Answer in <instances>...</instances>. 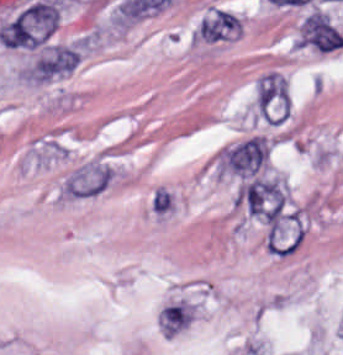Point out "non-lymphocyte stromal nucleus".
<instances>
[{
	"mask_svg": "<svg viewBox=\"0 0 343 355\" xmlns=\"http://www.w3.org/2000/svg\"><path fill=\"white\" fill-rule=\"evenodd\" d=\"M243 207L261 221L277 226L284 219L285 196L274 180L251 176L240 191Z\"/></svg>",
	"mask_w": 343,
	"mask_h": 355,
	"instance_id": "dd21d789",
	"label": "non-lymphocyte stromal nucleus"
},
{
	"mask_svg": "<svg viewBox=\"0 0 343 355\" xmlns=\"http://www.w3.org/2000/svg\"><path fill=\"white\" fill-rule=\"evenodd\" d=\"M114 173L109 163L87 160L73 168L60 182L59 193L63 196H95L106 187Z\"/></svg>",
	"mask_w": 343,
	"mask_h": 355,
	"instance_id": "a72fc3eb",
	"label": "non-lymphocyte stromal nucleus"
},
{
	"mask_svg": "<svg viewBox=\"0 0 343 355\" xmlns=\"http://www.w3.org/2000/svg\"><path fill=\"white\" fill-rule=\"evenodd\" d=\"M300 45L328 51L343 45V37L326 14L314 11L303 22Z\"/></svg>",
	"mask_w": 343,
	"mask_h": 355,
	"instance_id": "3746e769",
	"label": "non-lymphocyte stromal nucleus"
},
{
	"mask_svg": "<svg viewBox=\"0 0 343 355\" xmlns=\"http://www.w3.org/2000/svg\"><path fill=\"white\" fill-rule=\"evenodd\" d=\"M266 150L262 137H248L226 152L225 161L232 171L253 172Z\"/></svg>",
	"mask_w": 343,
	"mask_h": 355,
	"instance_id": "fc2b8d12",
	"label": "non-lymphocyte stromal nucleus"
},
{
	"mask_svg": "<svg viewBox=\"0 0 343 355\" xmlns=\"http://www.w3.org/2000/svg\"><path fill=\"white\" fill-rule=\"evenodd\" d=\"M79 54L65 45H52L37 59V72L40 76H51L70 70L77 62Z\"/></svg>",
	"mask_w": 343,
	"mask_h": 355,
	"instance_id": "81446118",
	"label": "non-lymphocyte stromal nucleus"
},
{
	"mask_svg": "<svg viewBox=\"0 0 343 355\" xmlns=\"http://www.w3.org/2000/svg\"><path fill=\"white\" fill-rule=\"evenodd\" d=\"M162 329L170 332H176L186 324H188L191 314L183 305V303H169L163 307L159 314Z\"/></svg>",
	"mask_w": 343,
	"mask_h": 355,
	"instance_id": "7c5642bf",
	"label": "non-lymphocyte stromal nucleus"
},
{
	"mask_svg": "<svg viewBox=\"0 0 343 355\" xmlns=\"http://www.w3.org/2000/svg\"><path fill=\"white\" fill-rule=\"evenodd\" d=\"M175 205L176 201L173 191L162 185L154 187L150 196V210L154 216L162 218L168 216L175 208Z\"/></svg>",
	"mask_w": 343,
	"mask_h": 355,
	"instance_id": "9d01c50a",
	"label": "non-lymphocyte stromal nucleus"
}]
</instances>
